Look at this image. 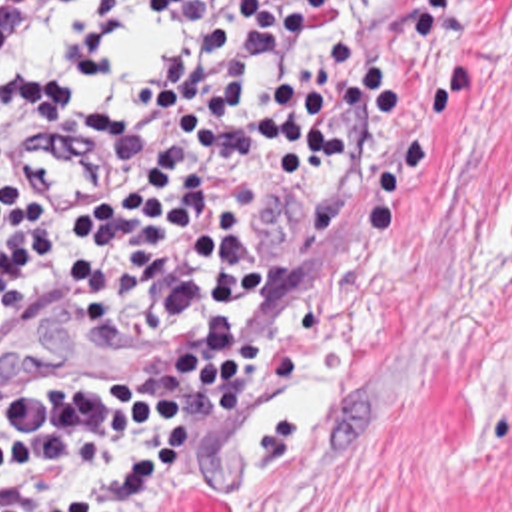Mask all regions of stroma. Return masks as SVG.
<instances>
[{
    "instance_id": "stroma-1",
    "label": "stroma",
    "mask_w": 512,
    "mask_h": 512,
    "mask_svg": "<svg viewBox=\"0 0 512 512\" xmlns=\"http://www.w3.org/2000/svg\"><path fill=\"white\" fill-rule=\"evenodd\" d=\"M395 85L367 147H271L269 271L213 337L45 313L0 377H177L267 341L137 512H512V0H343Z\"/></svg>"
}]
</instances>
